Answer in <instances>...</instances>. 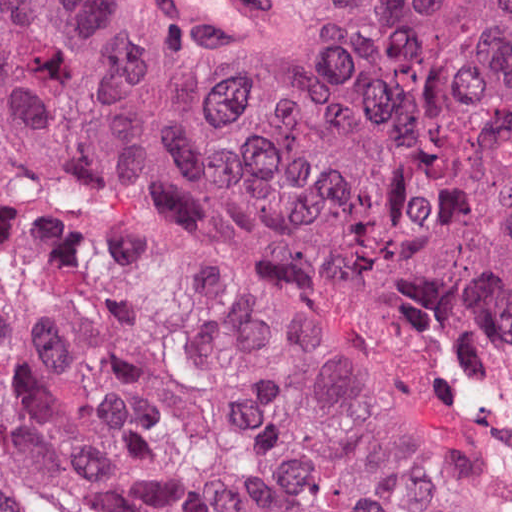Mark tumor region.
Instances as JSON below:
<instances>
[{"mask_svg":"<svg viewBox=\"0 0 512 512\" xmlns=\"http://www.w3.org/2000/svg\"><path fill=\"white\" fill-rule=\"evenodd\" d=\"M240 93L138 0H0V512H465L512 337V0H277Z\"/></svg>","mask_w":512,"mask_h":512,"instance_id":"e687c5a6","label":"tumor region"}]
</instances>
